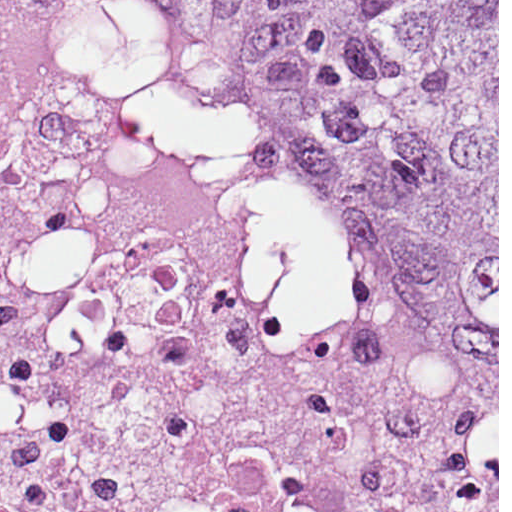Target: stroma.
<instances>
[{
    "instance_id": "stroma-1",
    "label": "stroma",
    "mask_w": 512,
    "mask_h": 512,
    "mask_svg": "<svg viewBox=\"0 0 512 512\" xmlns=\"http://www.w3.org/2000/svg\"><path fill=\"white\" fill-rule=\"evenodd\" d=\"M485 407L461 412L472 441L497 462V512H499V0H497V408L486 397L470 398Z\"/></svg>"
}]
</instances>
